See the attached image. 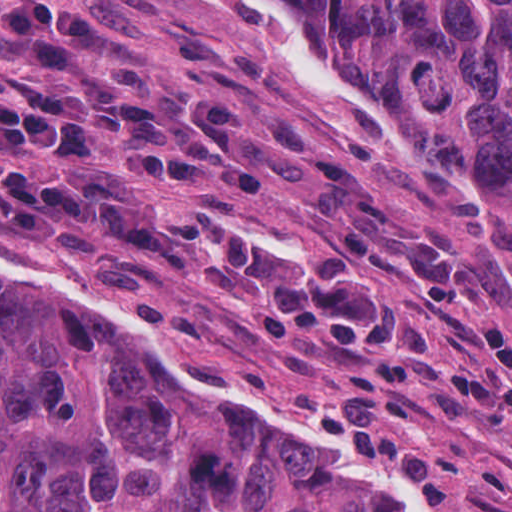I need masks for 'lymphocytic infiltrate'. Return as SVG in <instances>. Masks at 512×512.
Listing matches in <instances>:
<instances>
[{
    "label": "lymphocytic infiltrate",
    "mask_w": 512,
    "mask_h": 512,
    "mask_svg": "<svg viewBox=\"0 0 512 512\" xmlns=\"http://www.w3.org/2000/svg\"><path fill=\"white\" fill-rule=\"evenodd\" d=\"M0 31L58 69L48 79L15 73V89L0 93V144L13 155L79 168L96 141H111L116 174L161 184L175 197H193L204 171L248 197L267 194V175L242 140L243 105L176 109L161 103L152 71L136 59L102 70L92 58L109 31L90 5L3 4ZM0 216L33 248L98 250L108 282L123 288L156 285L168 273L234 280L280 341L315 336L335 358L367 359L345 386L344 441L421 477L440 506L456 504L447 469L390 417L417 399L401 373L412 343L402 333L403 299L371 266L272 242L246 219L178 234L118 182L91 172L56 182L3 160Z\"/></svg>",
    "instance_id": "1"
}]
</instances>
